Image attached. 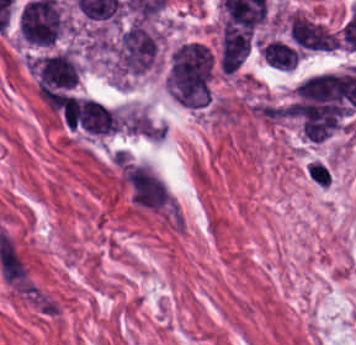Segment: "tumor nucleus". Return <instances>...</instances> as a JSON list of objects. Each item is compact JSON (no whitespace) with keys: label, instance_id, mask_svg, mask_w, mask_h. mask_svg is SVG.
<instances>
[{"label":"tumor nucleus","instance_id":"tumor-nucleus-1","mask_svg":"<svg viewBox=\"0 0 356 345\" xmlns=\"http://www.w3.org/2000/svg\"><path fill=\"white\" fill-rule=\"evenodd\" d=\"M288 30L295 44L304 50H330L337 43L336 35L324 24L300 13L291 15Z\"/></svg>","mask_w":356,"mask_h":345},{"label":"tumor nucleus","instance_id":"tumor-nucleus-2","mask_svg":"<svg viewBox=\"0 0 356 345\" xmlns=\"http://www.w3.org/2000/svg\"><path fill=\"white\" fill-rule=\"evenodd\" d=\"M265 62L283 71H292L296 65L297 54L293 48L282 41L270 40L262 49Z\"/></svg>","mask_w":356,"mask_h":345}]
</instances>
